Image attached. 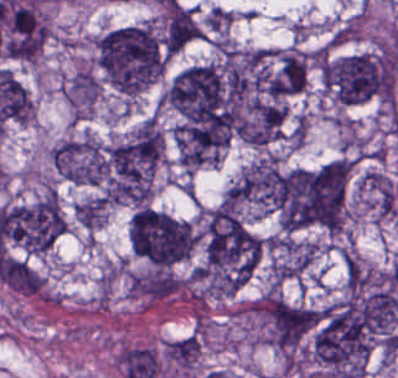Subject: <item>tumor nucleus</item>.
Segmentation results:
<instances>
[{"label":"tumor nucleus","instance_id":"tumor-nucleus-2","mask_svg":"<svg viewBox=\"0 0 398 378\" xmlns=\"http://www.w3.org/2000/svg\"><path fill=\"white\" fill-rule=\"evenodd\" d=\"M260 241L234 202L202 218L196 275L215 285H241L256 267Z\"/></svg>","mask_w":398,"mask_h":378},{"label":"tumor nucleus","instance_id":"tumor-nucleus-9","mask_svg":"<svg viewBox=\"0 0 398 378\" xmlns=\"http://www.w3.org/2000/svg\"><path fill=\"white\" fill-rule=\"evenodd\" d=\"M281 174L276 154H263L249 163L226 190L225 196L267 212L278 209Z\"/></svg>","mask_w":398,"mask_h":378},{"label":"tumor nucleus","instance_id":"tumor-nucleus-4","mask_svg":"<svg viewBox=\"0 0 398 378\" xmlns=\"http://www.w3.org/2000/svg\"><path fill=\"white\" fill-rule=\"evenodd\" d=\"M370 347L369 331L341 300L314 311L311 355L330 378L362 373Z\"/></svg>","mask_w":398,"mask_h":378},{"label":"tumor nucleus","instance_id":"tumor-nucleus-7","mask_svg":"<svg viewBox=\"0 0 398 378\" xmlns=\"http://www.w3.org/2000/svg\"><path fill=\"white\" fill-rule=\"evenodd\" d=\"M127 237L132 253L165 268L187 256L197 234L186 219L139 206L129 218Z\"/></svg>","mask_w":398,"mask_h":378},{"label":"tumor nucleus","instance_id":"tumor-nucleus-5","mask_svg":"<svg viewBox=\"0 0 398 378\" xmlns=\"http://www.w3.org/2000/svg\"><path fill=\"white\" fill-rule=\"evenodd\" d=\"M340 305L354 328L391 331L398 316L397 294L387 272L346 253Z\"/></svg>","mask_w":398,"mask_h":378},{"label":"tumor nucleus","instance_id":"tumor-nucleus-12","mask_svg":"<svg viewBox=\"0 0 398 378\" xmlns=\"http://www.w3.org/2000/svg\"><path fill=\"white\" fill-rule=\"evenodd\" d=\"M72 210L79 224L92 228L104 217L105 201L94 195L73 205Z\"/></svg>","mask_w":398,"mask_h":378},{"label":"tumor nucleus","instance_id":"tumor-nucleus-11","mask_svg":"<svg viewBox=\"0 0 398 378\" xmlns=\"http://www.w3.org/2000/svg\"><path fill=\"white\" fill-rule=\"evenodd\" d=\"M99 93L95 78L87 71L76 72L69 80L66 98L74 105L88 108Z\"/></svg>","mask_w":398,"mask_h":378},{"label":"tumor nucleus","instance_id":"tumor-nucleus-8","mask_svg":"<svg viewBox=\"0 0 398 378\" xmlns=\"http://www.w3.org/2000/svg\"><path fill=\"white\" fill-rule=\"evenodd\" d=\"M0 226L14 246L30 255L46 253L63 227L55 193L46 192L3 207Z\"/></svg>","mask_w":398,"mask_h":378},{"label":"tumor nucleus","instance_id":"tumor-nucleus-6","mask_svg":"<svg viewBox=\"0 0 398 378\" xmlns=\"http://www.w3.org/2000/svg\"><path fill=\"white\" fill-rule=\"evenodd\" d=\"M323 88L341 104L388 101L389 59L386 52H354L324 60Z\"/></svg>","mask_w":398,"mask_h":378},{"label":"tumor nucleus","instance_id":"tumor-nucleus-10","mask_svg":"<svg viewBox=\"0 0 398 378\" xmlns=\"http://www.w3.org/2000/svg\"><path fill=\"white\" fill-rule=\"evenodd\" d=\"M202 34V28L188 6L170 1L164 11L160 45L167 56L179 51Z\"/></svg>","mask_w":398,"mask_h":378},{"label":"tumor nucleus","instance_id":"tumor-nucleus-1","mask_svg":"<svg viewBox=\"0 0 398 378\" xmlns=\"http://www.w3.org/2000/svg\"><path fill=\"white\" fill-rule=\"evenodd\" d=\"M300 80L291 51L226 48L225 89L235 130L266 145Z\"/></svg>","mask_w":398,"mask_h":378},{"label":"tumor nucleus","instance_id":"tumor-nucleus-3","mask_svg":"<svg viewBox=\"0 0 398 378\" xmlns=\"http://www.w3.org/2000/svg\"><path fill=\"white\" fill-rule=\"evenodd\" d=\"M94 53L103 80L125 95L153 81L162 65L160 35L143 22L102 32L94 41Z\"/></svg>","mask_w":398,"mask_h":378}]
</instances>
